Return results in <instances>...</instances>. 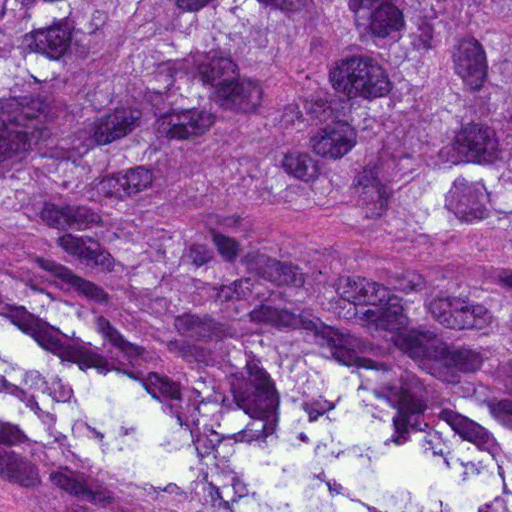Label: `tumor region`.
Instances as JSON below:
<instances>
[{
    "label": "tumor region",
    "mask_w": 512,
    "mask_h": 512,
    "mask_svg": "<svg viewBox=\"0 0 512 512\" xmlns=\"http://www.w3.org/2000/svg\"><path fill=\"white\" fill-rule=\"evenodd\" d=\"M0 512H512V0H0Z\"/></svg>",
    "instance_id": "e687c5a6"
}]
</instances>
